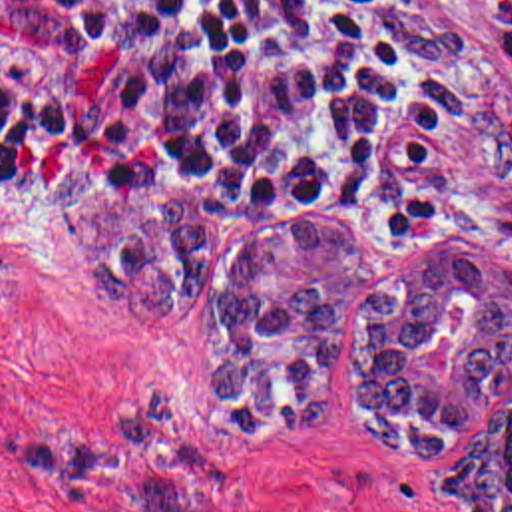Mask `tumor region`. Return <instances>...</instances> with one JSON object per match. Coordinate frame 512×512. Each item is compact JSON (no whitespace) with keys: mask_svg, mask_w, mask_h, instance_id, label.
Returning a JSON list of instances; mask_svg holds the SVG:
<instances>
[{"mask_svg":"<svg viewBox=\"0 0 512 512\" xmlns=\"http://www.w3.org/2000/svg\"><path fill=\"white\" fill-rule=\"evenodd\" d=\"M81 181L75 165H58L44 195L91 276L143 306H203L209 209L199 195L117 189L81 201ZM368 273L370 247L328 223L277 229L233 257L213 416L245 438L320 426L336 402L332 356L350 286ZM510 378L512 249L488 231L462 229L364 290L350 424L400 458H446L440 492L456 512H512ZM14 454L85 512L229 509L219 464L165 388L87 434L28 432Z\"/></svg>","mask_w":512,"mask_h":512,"instance_id":"obj_1","label":"tumor region"}]
</instances>
